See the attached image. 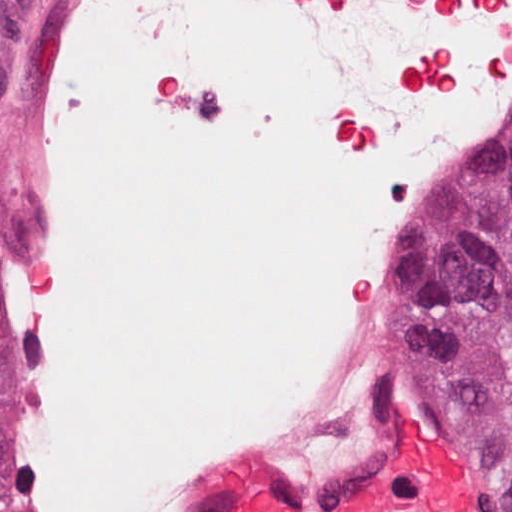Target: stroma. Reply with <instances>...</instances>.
<instances>
[{
    "label": "stroma",
    "mask_w": 512,
    "mask_h": 512,
    "mask_svg": "<svg viewBox=\"0 0 512 512\" xmlns=\"http://www.w3.org/2000/svg\"><path fill=\"white\" fill-rule=\"evenodd\" d=\"M49 0H0V171L10 203L0 253L34 251L33 211L18 154L29 36ZM11 499V403L0 340V512Z\"/></svg>",
    "instance_id": "1"
}]
</instances>
